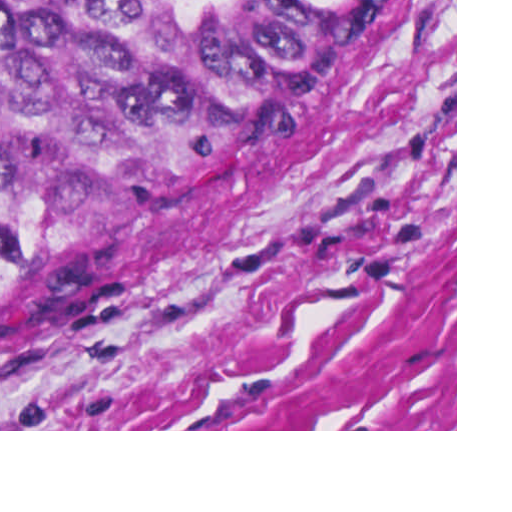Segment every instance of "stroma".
<instances>
[{
	"mask_svg": "<svg viewBox=\"0 0 512 512\" xmlns=\"http://www.w3.org/2000/svg\"><path fill=\"white\" fill-rule=\"evenodd\" d=\"M0 431H457V0H377Z\"/></svg>",
	"mask_w": 512,
	"mask_h": 512,
	"instance_id": "stroma-1",
	"label": "stroma"
}]
</instances>
